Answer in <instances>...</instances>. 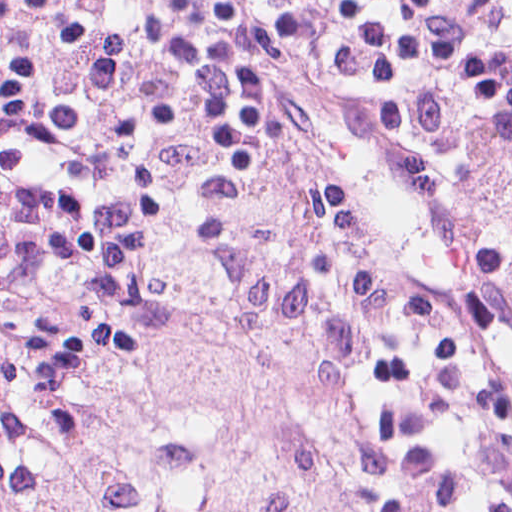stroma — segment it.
<instances>
[{
  "instance_id": "1",
  "label": "stroma",
  "mask_w": 512,
  "mask_h": 512,
  "mask_svg": "<svg viewBox=\"0 0 512 512\" xmlns=\"http://www.w3.org/2000/svg\"><path fill=\"white\" fill-rule=\"evenodd\" d=\"M284 100L271 137L224 153L171 209L155 299L104 343L38 363L0 319V413L82 428L123 328L216 298L221 261L292 258L357 349L354 455L314 512H512V273L379 127L298 77Z\"/></svg>"
}]
</instances>
